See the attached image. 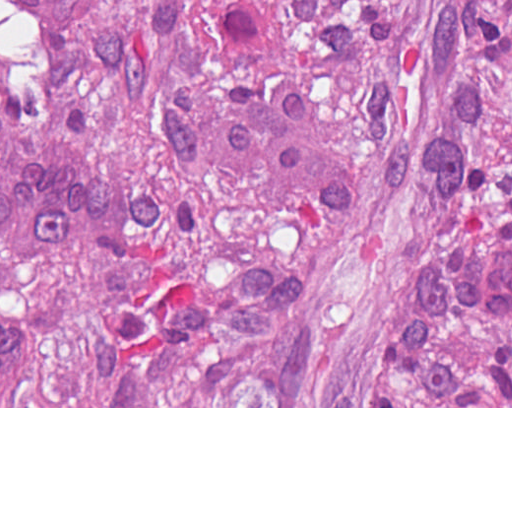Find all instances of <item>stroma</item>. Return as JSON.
<instances>
[{"label":"stroma","instance_id":"stroma-1","mask_svg":"<svg viewBox=\"0 0 512 512\" xmlns=\"http://www.w3.org/2000/svg\"><path fill=\"white\" fill-rule=\"evenodd\" d=\"M0 408H512V406H0Z\"/></svg>","mask_w":512,"mask_h":512}]
</instances>
